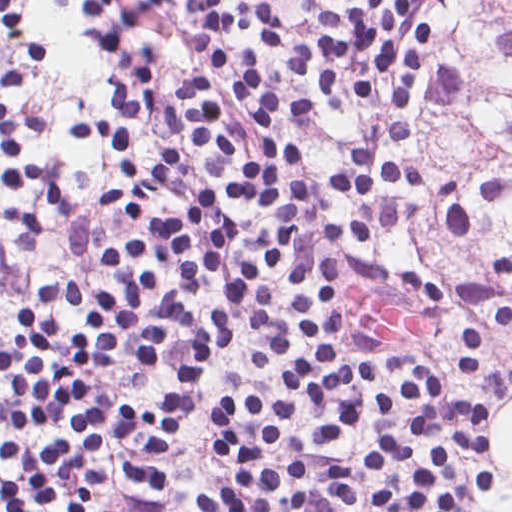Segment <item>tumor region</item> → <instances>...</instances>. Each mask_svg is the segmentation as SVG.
<instances>
[{
    "label": "tumor region",
    "mask_w": 512,
    "mask_h": 512,
    "mask_svg": "<svg viewBox=\"0 0 512 512\" xmlns=\"http://www.w3.org/2000/svg\"><path fill=\"white\" fill-rule=\"evenodd\" d=\"M453 43L434 84L427 134L457 166L512 167V0H448ZM451 278L462 294L451 351L512 399V234L464 265L461 291L446 241L394 239Z\"/></svg>",
    "instance_id": "1"
}]
</instances>
